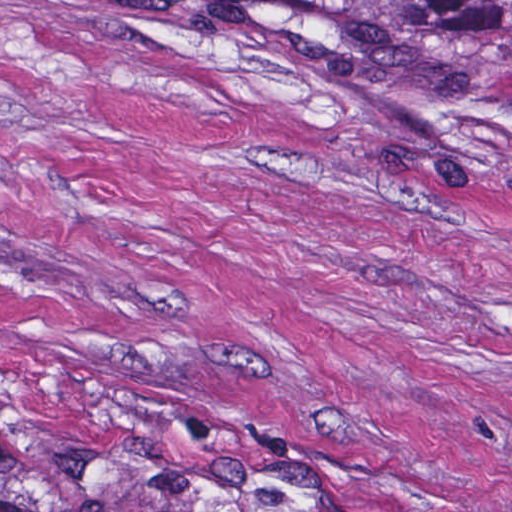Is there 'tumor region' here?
Wrapping results in <instances>:
<instances>
[{
    "label": "tumor region",
    "instance_id": "tumor-region-1",
    "mask_svg": "<svg viewBox=\"0 0 512 512\" xmlns=\"http://www.w3.org/2000/svg\"><path fill=\"white\" fill-rule=\"evenodd\" d=\"M384 88L473 95L512 69V0H157ZM0 512L209 511L91 434L0 392Z\"/></svg>",
    "mask_w": 512,
    "mask_h": 512
}]
</instances>
